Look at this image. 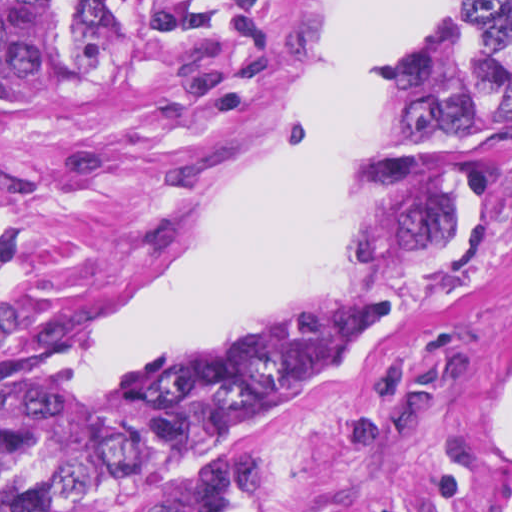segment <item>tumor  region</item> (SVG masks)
Wrapping results in <instances>:
<instances>
[{
    "label": "tumor region",
    "mask_w": 512,
    "mask_h": 512,
    "mask_svg": "<svg viewBox=\"0 0 512 512\" xmlns=\"http://www.w3.org/2000/svg\"><path fill=\"white\" fill-rule=\"evenodd\" d=\"M213 42L199 0H1V121ZM358 178V279L166 373L91 395L71 375L62 305L3 301L1 512H256L228 477L248 440L394 337L488 244L512 186V0L458 2L384 97Z\"/></svg>",
    "instance_id": "1"
}]
</instances>
